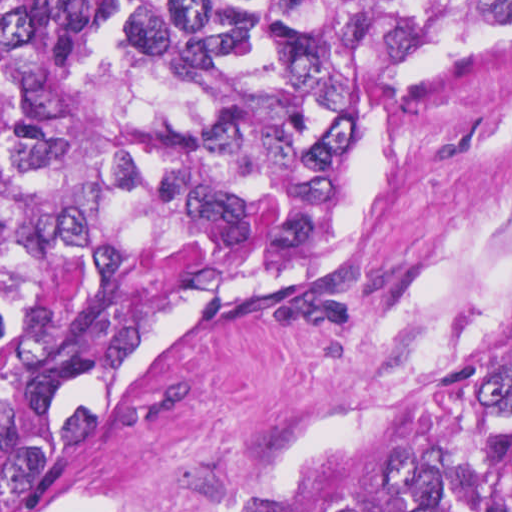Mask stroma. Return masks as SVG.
<instances>
[{
  "mask_svg": "<svg viewBox=\"0 0 512 512\" xmlns=\"http://www.w3.org/2000/svg\"><path fill=\"white\" fill-rule=\"evenodd\" d=\"M511 317L512 32L371 98L322 263L199 297L153 333L78 403L101 424L19 511L205 506Z\"/></svg>",
  "mask_w": 512,
  "mask_h": 512,
  "instance_id": "1",
  "label": "stroma"
}]
</instances>
